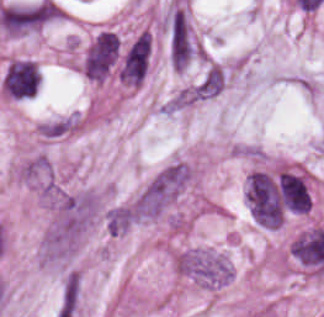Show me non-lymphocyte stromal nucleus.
I'll return each mask as SVG.
<instances>
[{"instance_id": "dd21d789", "label": "non-lymphocyte stromal nucleus", "mask_w": 324, "mask_h": 317, "mask_svg": "<svg viewBox=\"0 0 324 317\" xmlns=\"http://www.w3.org/2000/svg\"><path fill=\"white\" fill-rule=\"evenodd\" d=\"M192 173L185 163L163 166L134 199V214L157 216L189 182Z\"/></svg>"}, {"instance_id": "a72fc3eb", "label": "non-lymphocyte stromal nucleus", "mask_w": 324, "mask_h": 317, "mask_svg": "<svg viewBox=\"0 0 324 317\" xmlns=\"http://www.w3.org/2000/svg\"><path fill=\"white\" fill-rule=\"evenodd\" d=\"M178 270L207 285L229 282L232 269L229 261L204 250L192 249L176 258Z\"/></svg>"}, {"instance_id": "3746e769", "label": "non-lymphocyte stromal nucleus", "mask_w": 324, "mask_h": 317, "mask_svg": "<svg viewBox=\"0 0 324 317\" xmlns=\"http://www.w3.org/2000/svg\"><path fill=\"white\" fill-rule=\"evenodd\" d=\"M80 275L78 271L67 274L61 292L59 316L73 313L78 307Z\"/></svg>"}, {"instance_id": "fc2b8d12", "label": "non-lymphocyte stromal nucleus", "mask_w": 324, "mask_h": 317, "mask_svg": "<svg viewBox=\"0 0 324 317\" xmlns=\"http://www.w3.org/2000/svg\"><path fill=\"white\" fill-rule=\"evenodd\" d=\"M105 219L109 234L118 235L135 221L134 210L129 204L120 203L107 212Z\"/></svg>"}]
</instances>
